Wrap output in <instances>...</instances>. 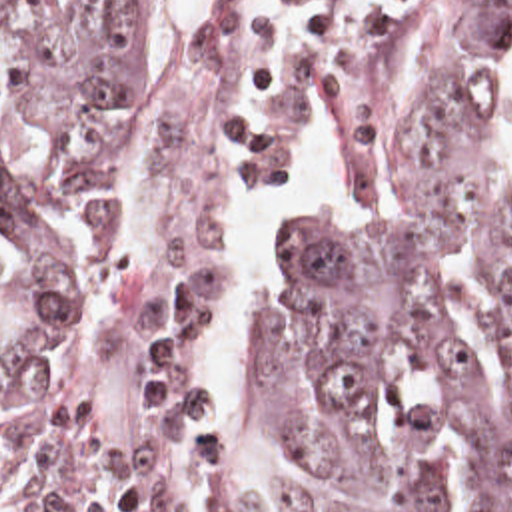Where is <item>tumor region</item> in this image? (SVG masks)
<instances>
[{
	"mask_svg": "<svg viewBox=\"0 0 512 512\" xmlns=\"http://www.w3.org/2000/svg\"><path fill=\"white\" fill-rule=\"evenodd\" d=\"M236 2L166 90L152 0H0V512H176L206 453L196 310L256 124ZM348 74L338 200L268 264L256 411L292 512H512V0H300Z\"/></svg>",
	"mask_w": 512,
	"mask_h": 512,
	"instance_id": "e687c5a6",
	"label": "tumor region"
}]
</instances>
